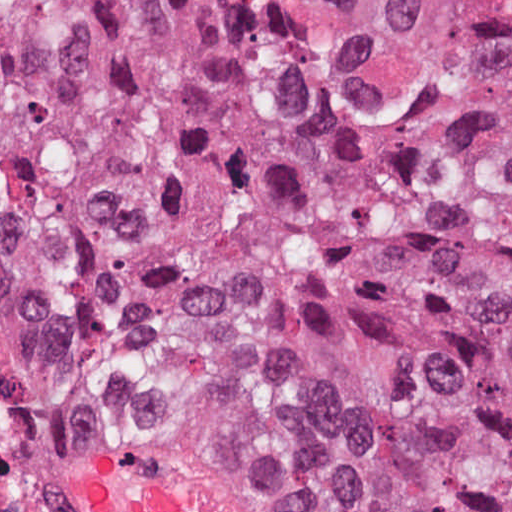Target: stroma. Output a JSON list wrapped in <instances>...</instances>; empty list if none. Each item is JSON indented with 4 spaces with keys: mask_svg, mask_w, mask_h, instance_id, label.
<instances>
[{
    "mask_svg": "<svg viewBox=\"0 0 512 512\" xmlns=\"http://www.w3.org/2000/svg\"><path fill=\"white\" fill-rule=\"evenodd\" d=\"M0 324L25 361L29 383L73 463L78 494L93 455H103L151 481L234 512H310L308 505L257 476L218 467L187 450L84 433L56 411L46 382L29 350L15 302L1 287Z\"/></svg>",
    "mask_w": 512,
    "mask_h": 512,
    "instance_id": "35a3bbf8",
    "label": "stroma"
}]
</instances>
